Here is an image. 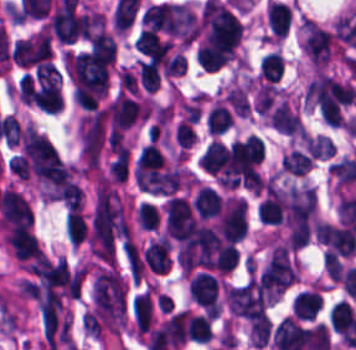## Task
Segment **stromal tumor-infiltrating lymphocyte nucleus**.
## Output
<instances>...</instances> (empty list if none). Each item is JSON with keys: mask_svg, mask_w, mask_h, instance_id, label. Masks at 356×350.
<instances>
[{"mask_svg": "<svg viewBox=\"0 0 356 350\" xmlns=\"http://www.w3.org/2000/svg\"><path fill=\"white\" fill-rule=\"evenodd\" d=\"M56 38L62 42H74L91 33V17L86 13H71L50 22Z\"/></svg>", "mask_w": 356, "mask_h": 350, "instance_id": "stromal-tumor-infiltrating-lymphocyte-nucleus-5", "label": "stromal tumor-infiltrating lymphocyte nucleus"}, {"mask_svg": "<svg viewBox=\"0 0 356 350\" xmlns=\"http://www.w3.org/2000/svg\"><path fill=\"white\" fill-rule=\"evenodd\" d=\"M283 65L282 54L273 51L260 58L259 72L263 78L276 82L282 74Z\"/></svg>", "mask_w": 356, "mask_h": 350, "instance_id": "stromal-tumor-infiltrating-lymphocyte-nucleus-17", "label": "stromal tumor-infiltrating lymphocyte nucleus"}, {"mask_svg": "<svg viewBox=\"0 0 356 350\" xmlns=\"http://www.w3.org/2000/svg\"><path fill=\"white\" fill-rule=\"evenodd\" d=\"M228 299L235 314L252 319L268 314V299L253 276L231 286Z\"/></svg>", "mask_w": 356, "mask_h": 350, "instance_id": "stromal-tumor-infiltrating-lymphocyte-nucleus-3", "label": "stromal tumor-infiltrating lymphocyte nucleus"}, {"mask_svg": "<svg viewBox=\"0 0 356 350\" xmlns=\"http://www.w3.org/2000/svg\"><path fill=\"white\" fill-rule=\"evenodd\" d=\"M141 104L121 90L114 96L106 113L115 129H124L131 125L141 112Z\"/></svg>", "mask_w": 356, "mask_h": 350, "instance_id": "stromal-tumor-infiltrating-lymphocyte-nucleus-7", "label": "stromal tumor-infiltrating lymphocyte nucleus"}, {"mask_svg": "<svg viewBox=\"0 0 356 350\" xmlns=\"http://www.w3.org/2000/svg\"><path fill=\"white\" fill-rule=\"evenodd\" d=\"M65 229L71 244L79 245L85 241L86 224L80 211L70 210L66 216Z\"/></svg>", "mask_w": 356, "mask_h": 350, "instance_id": "stromal-tumor-infiltrating-lymphocyte-nucleus-16", "label": "stromal tumor-infiltrating lymphocyte nucleus"}, {"mask_svg": "<svg viewBox=\"0 0 356 350\" xmlns=\"http://www.w3.org/2000/svg\"><path fill=\"white\" fill-rule=\"evenodd\" d=\"M297 271L289 251L276 246L258 282L259 289L271 301L277 299L296 277Z\"/></svg>", "mask_w": 356, "mask_h": 350, "instance_id": "stromal-tumor-infiltrating-lymphocyte-nucleus-2", "label": "stromal tumor-infiltrating lymphocyte nucleus"}, {"mask_svg": "<svg viewBox=\"0 0 356 350\" xmlns=\"http://www.w3.org/2000/svg\"><path fill=\"white\" fill-rule=\"evenodd\" d=\"M269 120L274 128L286 134L291 135L302 129L301 119L284 99L272 110Z\"/></svg>", "mask_w": 356, "mask_h": 350, "instance_id": "stromal-tumor-infiltrating-lymphocyte-nucleus-10", "label": "stromal tumor-infiltrating lymphocyte nucleus"}, {"mask_svg": "<svg viewBox=\"0 0 356 350\" xmlns=\"http://www.w3.org/2000/svg\"><path fill=\"white\" fill-rule=\"evenodd\" d=\"M285 215L291 241L307 242L316 212V191L311 186H290Z\"/></svg>", "mask_w": 356, "mask_h": 350, "instance_id": "stromal-tumor-infiltrating-lymphocyte-nucleus-1", "label": "stromal tumor-infiltrating lymphocyte nucleus"}, {"mask_svg": "<svg viewBox=\"0 0 356 350\" xmlns=\"http://www.w3.org/2000/svg\"><path fill=\"white\" fill-rule=\"evenodd\" d=\"M291 20V8L287 2L270 0L268 2V21L275 37H282Z\"/></svg>", "mask_w": 356, "mask_h": 350, "instance_id": "stromal-tumor-infiltrating-lymphocyte-nucleus-12", "label": "stromal tumor-infiltrating lymphocyte nucleus"}, {"mask_svg": "<svg viewBox=\"0 0 356 350\" xmlns=\"http://www.w3.org/2000/svg\"><path fill=\"white\" fill-rule=\"evenodd\" d=\"M136 45L137 50L152 59H163L169 50V41L146 27L137 35Z\"/></svg>", "mask_w": 356, "mask_h": 350, "instance_id": "stromal-tumor-infiltrating-lymphocyte-nucleus-11", "label": "stromal tumor-infiltrating lymphocyte nucleus"}, {"mask_svg": "<svg viewBox=\"0 0 356 350\" xmlns=\"http://www.w3.org/2000/svg\"><path fill=\"white\" fill-rule=\"evenodd\" d=\"M188 294L206 308H218L217 278L205 271H198L189 281Z\"/></svg>", "mask_w": 356, "mask_h": 350, "instance_id": "stromal-tumor-infiltrating-lymphocyte-nucleus-8", "label": "stromal tumor-infiltrating lymphocyte nucleus"}, {"mask_svg": "<svg viewBox=\"0 0 356 350\" xmlns=\"http://www.w3.org/2000/svg\"><path fill=\"white\" fill-rule=\"evenodd\" d=\"M136 161L161 169L163 165V154L154 141L142 145Z\"/></svg>", "mask_w": 356, "mask_h": 350, "instance_id": "stromal-tumor-infiltrating-lymphocyte-nucleus-20", "label": "stromal tumor-infiltrating lymphocyte nucleus"}, {"mask_svg": "<svg viewBox=\"0 0 356 350\" xmlns=\"http://www.w3.org/2000/svg\"><path fill=\"white\" fill-rule=\"evenodd\" d=\"M187 337L197 342L210 340L209 317L203 314H189L187 318Z\"/></svg>", "mask_w": 356, "mask_h": 350, "instance_id": "stromal-tumor-infiltrating-lymphocyte-nucleus-14", "label": "stromal tumor-infiltrating lymphocyte nucleus"}, {"mask_svg": "<svg viewBox=\"0 0 356 350\" xmlns=\"http://www.w3.org/2000/svg\"><path fill=\"white\" fill-rule=\"evenodd\" d=\"M232 120L233 118L229 109L217 102L208 111L206 125L208 129L219 134L230 126Z\"/></svg>", "mask_w": 356, "mask_h": 350, "instance_id": "stromal-tumor-infiltrating-lymphocyte-nucleus-15", "label": "stromal tumor-infiltrating lymphocyte nucleus"}, {"mask_svg": "<svg viewBox=\"0 0 356 350\" xmlns=\"http://www.w3.org/2000/svg\"><path fill=\"white\" fill-rule=\"evenodd\" d=\"M140 78L148 91H156L160 81L161 72L153 61H140Z\"/></svg>", "mask_w": 356, "mask_h": 350, "instance_id": "stromal-tumor-infiltrating-lymphocyte-nucleus-19", "label": "stromal tumor-infiltrating lymphocyte nucleus"}, {"mask_svg": "<svg viewBox=\"0 0 356 350\" xmlns=\"http://www.w3.org/2000/svg\"><path fill=\"white\" fill-rule=\"evenodd\" d=\"M63 201L69 210H80L82 208V193L80 186L75 182H68L60 192Z\"/></svg>", "mask_w": 356, "mask_h": 350, "instance_id": "stromal-tumor-infiltrating-lymphocyte-nucleus-21", "label": "stromal tumor-infiltrating lymphocyte nucleus"}, {"mask_svg": "<svg viewBox=\"0 0 356 350\" xmlns=\"http://www.w3.org/2000/svg\"><path fill=\"white\" fill-rule=\"evenodd\" d=\"M272 324L268 314L250 322V336L253 345L265 346L270 339Z\"/></svg>", "mask_w": 356, "mask_h": 350, "instance_id": "stromal-tumor-infiltrating-lymphocyte-nucleus-18", "label": "stromal tumor-infiltrating lymphocyte nucleus"}, {"mask_svg": "<svg viewBox=\"0 0 356 350\" xmlns=\"http://www.w3.org/2000/svg\"><path fill=\"white\" fill-rule=\"evenodd\" d=\"M192 205L198 216L203 218H210L222 210L213 189L204 185L198 190Z\"/></svg>", "mask_w": 356, "mask_h": 350, "instance_id": "stromal-tumor-infiltrating-lymphocyte-nucleus-13", "label": "stromal tumor-infiltrating lymphocyte nucleus"}, {"mask_svg": "<svg viewBox=\"0 0 356 350\" xmlns=\"http://www.w3.org/2000/svg\"><path fill=\"white\" fill-rule=\"evenodd\" d=\"M262 223L280 224L285 221V194L282 189H269L258 205Z\"/></svg>", "mask_w": 356, "mask_h": 350, "instance_id": "stromal-tumor-infiltrating-lymphocyte-nucleus-9", "label": "stromal tumor-infiltrating lymphocyte nucleus"}, {"mask_svg": "<svg viewBox=\"0 0 356 350\" xmlns=\"http://www.w3.org/2000/svg\"><path fill=\"white\" fill-rule=\"evenodd\" d=\"M219 227L237 242L246 232L245 199L228 196L221 212Z\"/></svg>", "mask_w": 356, "mask_h": 350, "instance_id": "stromal-tumor-infiltrating-lymphocyte-nucleus-6", "label": "stromal tumor-infiltrating lymphocyte nucleus"}, {"mask_svg": "<svg viewBox=\"0 0 356 350\" xmlns=\"http://www.w3.org/2000/svg\"><path fill=\"white\" fill-rule=\"evenodd\" d=\"M303 48L310 61L322 68L331 57L333 35L318 22L304 17L301 22Z\"/></svg>", "mask_w": 356, "mask_h": 350, "instance_id": "stromal-tumor-infiltrating-lymphocyte-nucleus-4", "label": "stromal tumor-infiltrating lymphocyte nucleus"}]
</instances>
